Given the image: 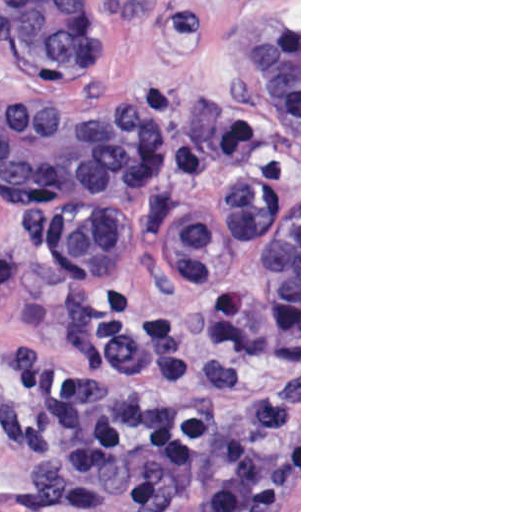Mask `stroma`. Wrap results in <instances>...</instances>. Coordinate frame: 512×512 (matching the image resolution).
Listing matches in <instances>:
<instances>
[{
	"instance_id": "35a3bbf8",
	"label": "stroma",
	"mask_w": 512,
	"mask_h": 512,
	"mask_svg": "<svg viewBox=\"0 0 512 512\" xmlns=\"http://www.w3.org/2000/svg\"><path fill=\"white\" fill-rule=\"evenodd\" d=\"M10 0H0V109L44 89L6 45ZM299 33V141L252 111L228 75L222 34ZM138 133L132 152L120 242V268L107 283L89 278L48 242L36 205L0 191V512H35L25 498L38 447L16 419L11 368L41 349L72 361L93 308L108 291L136 295L177 317L182 371L172 393L205 411L237 414L204 378L186 329L199 333L203 291L178 273L175 248L186 214L223 195L224 132L256 123L267 156L262 233L250 272V305L275 350L281 436L271 465L266 512H301V0H97V60L82 88ZM299 199V329L260 302L266 227ZM114 512H134L118 509Z\"/></svg>"
}]
</instances>
